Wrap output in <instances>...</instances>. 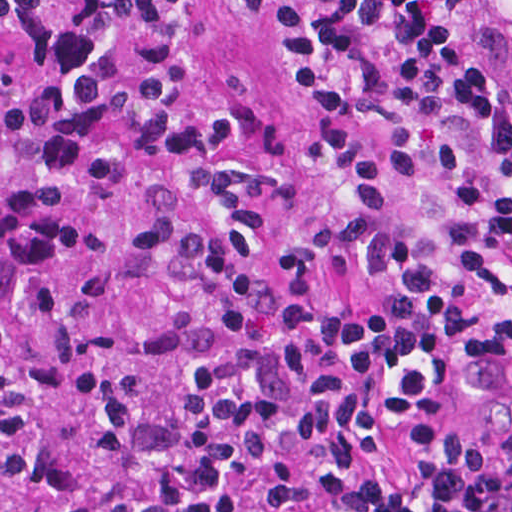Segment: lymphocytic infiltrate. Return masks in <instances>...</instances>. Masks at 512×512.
<instances>
[{"instance_id":"lymphocytic-infiltrate-1","label":"lymphocytic infiltrate","mask_w":512,"mask_h":512,"mask_svg":"<svg viewBox=\"0 0 512 512\" xmlns=\"http://www.w3.org/2000/svg\"><path fill=\"white\" fill-rule=\"evenodd\" d=\"M263 16L273 90L387 144L378 160L327 128L321 167L349 180L344 244L378 303L332 301L316 253L278 250L339 323L347 353L145 446L73 512H512V425L430 430L398 480L374 457L396 421L436 413L476 365L512 360V0H224ZM188 0H0V20L68 67L142 39L129 90H76L145 137L255 231L294 205L285 134L230 147L239 108L168 117Z\"/></svg>"}]
</instances>
